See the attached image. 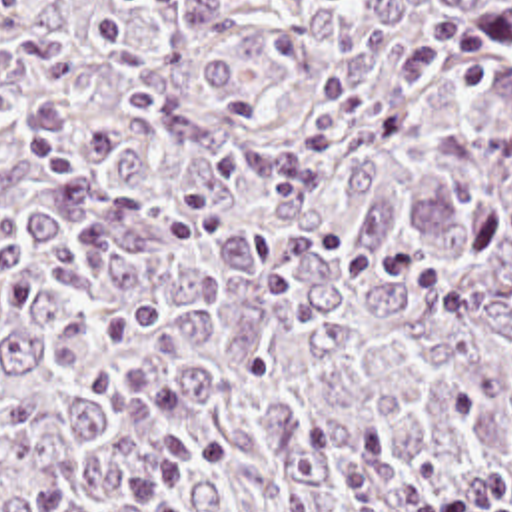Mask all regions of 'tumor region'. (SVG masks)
<instances>
[{
  "label": "tumor region",
  "instance_id": "obj_1",
  "mask_svg": "<svg viewBox=\"0 0 512 512\" xmlns=\"http://www.w3.org/2000/svg\"><path fill=\"white\" fill-rule=\"evenodd\" d=\"M479 468L512 512V0H0V512Z\"/></svg>",
  "mask_w": 512,
  "mask_h": 512
}]
</instances>
